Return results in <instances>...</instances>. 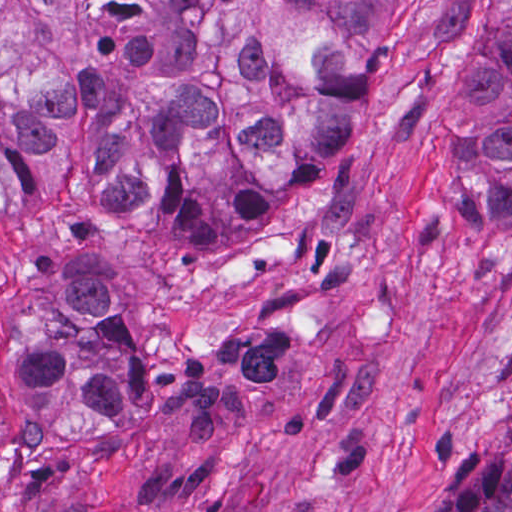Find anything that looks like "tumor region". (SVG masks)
<instances>
[{"instance_id":"tumor-region-1","label":"tumor region","mask_w":512,"mask_h":512,"mask_svg":"<svg viewBox=\"0 0 512 512\" xmlns=\"http://www.w3.org/2000/svg\"><path fill=\"white\" fill-rule=\"evenodd\" d=\"M466 0H1V442L135 411V314L364 131L380 49ZM464 94L475 176L435 223L512 226V0ZM444 512H512V428Z\"/></svg>"}]
</instances>
